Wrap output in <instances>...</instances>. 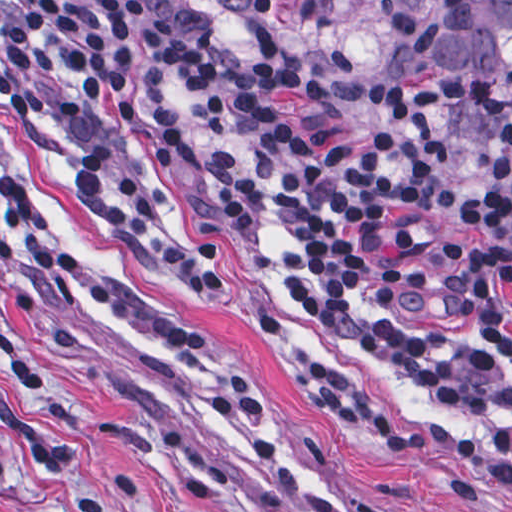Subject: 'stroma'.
Returning a JSON list of instances; mask_svg holds the SVG:
<instances>
[{
	"instance_id": "35a3bbf8",
	"label": "stroma",
	"mask_w": 512,
	"mask_h": 512,
	"mask_svg": "<svg viewBox=\"0 0 512 512\" xmlns=\"http://www.w3.org/2000/svg\"><path fill=\"white\" fill-rule=\"evenodd\" d=\"M143 8L193 49L266 78L183 37L166 16ZM168 112L179 133V166L172 173L154 169L138 119L131 129L138 190L158 219L220 248L228 288L218 300L195 302L164 285L127 247L89 224L74 207L70 169L57 144L42 128L3 109L0 167L52 210L66 247L116 288L171 319L220 331L274 404L296 490L283 492L204 440L190 402L204 375L200 366L124 345L69 293L31 281L18 287L19 299L0 308V512H512V496L475 464L446 454H379L318 413L276 370L257 325L275 321L291 327L308 348L450 432L493 434L512 443L511 416L465 419L382 367L365 345L373 324L410 321L449 331L512 364V344L491 337L473 313L445 311L432 264L441 243L470 239L460 202L476 187L478 167L466 159L452 164L451 206L428 247L437 277L432 299L416 309L368 310L353 325H337L285 289L276 263L280 228L265 231V251L256 265L203 225L195 208L203 192L204 158L190 97L179 95Z\"/></svg>"
}]
</instances>
